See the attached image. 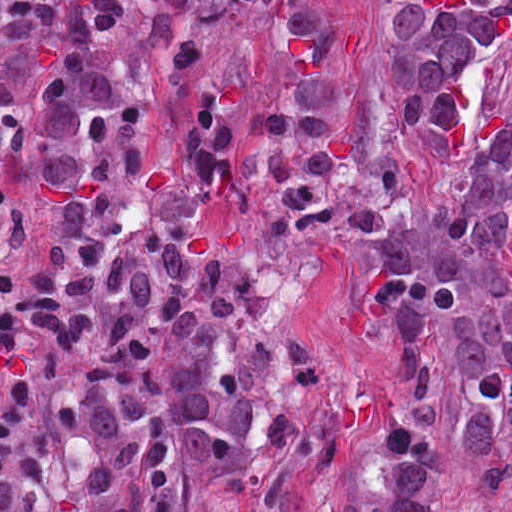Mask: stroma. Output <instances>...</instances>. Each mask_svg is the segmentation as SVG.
Wrapping results in <instances>:
<instances>
[{"mask_svg": "<svg viewBox=\"0 0 512 512\" xmlns=\"http://www.w3.org/2000/svg\"><path fill=\"white\" fill-rule=\"evenodd\" d=\"M348 61L363 86L351 128L400 166L412 189L405 223L396 231L346 237L334 231L300 234L289 245L248 263L240 279V315L458 216L470 198L477 160L493 139L512 134V29L484 52L472 75L466 119L455 131L405 130L389 97L382 58V0H365L348 14ZM512 193V155L506 166Z\"/></svg>", "mask_w": 512, "mask_h": 512, "instance_id": "stroma-1", "label": "stroma"}]
</instances>
